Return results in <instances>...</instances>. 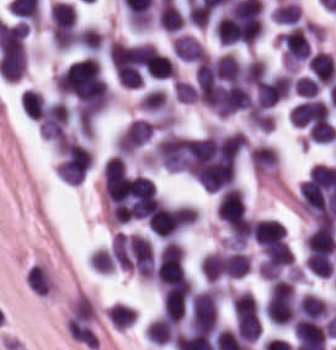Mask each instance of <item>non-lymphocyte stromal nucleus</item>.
I'll return each mask as SVG.
<instances>
[{"label":"non-lymphocyte stromal nucleus","instance_id":"non-lymphocyte-stromal-nucleus-1","mask_svg":"<svg viewBox=\"0 0 336 350\" xmlns=\"http://www.w3.org/2000/svg\"><path fill=\"white\" fill-rule=\"evenodd\" d=\"M22 278L27 292L32 297H52L56 287V279L47 263L34 260L26 264Z\"/></svg>","mask_w":336,"mask_h":350}]
</instances>
